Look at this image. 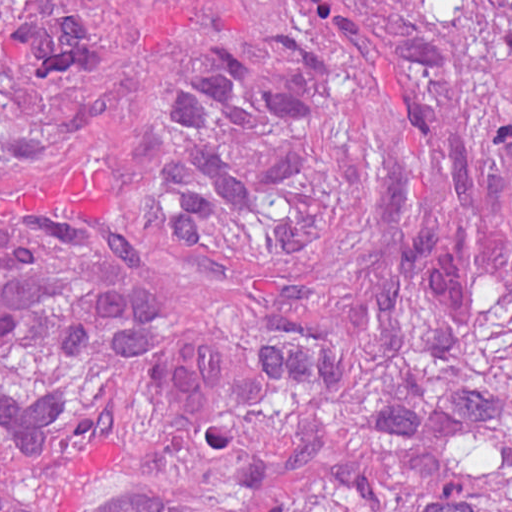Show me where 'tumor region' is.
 I'll return each instance as SVG.
<instances>
[{
  "instance_id": "e687c5a6",
  "label": "tumor region",
  "mask_w": 512,
  "mask_h": 512,
  "mask_svg": "<svg viewBox=\"0 0 512 512\" xmlns=\"http://www.w3.org/2000/svg\"><path fill=\"white\" fill-rule=\"evenodd\" d=\"M1 512H512V0H1Z\"/></svg>"
}]
</instances>
